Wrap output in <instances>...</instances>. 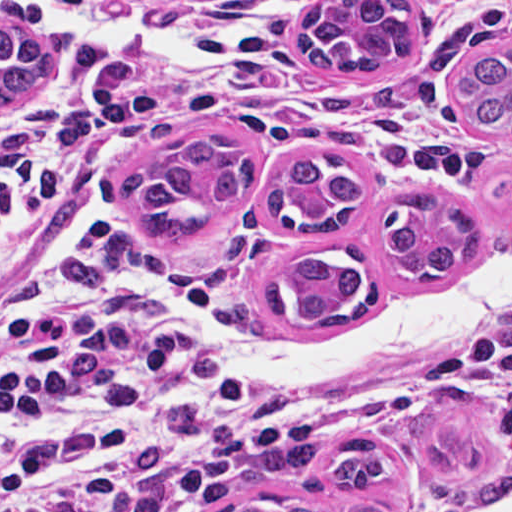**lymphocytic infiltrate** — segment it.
Returning <instances> with one entry per match:
<instances>
[{
    "instance_id": "1",
    "label": "lymphocytic infiltrate",
    "mask_w": 512,
    "mask_h": 512,
    "mask_svg": "<svg viewBox=\"0 0 512 512\" xmlns=\"http://www.w3.org/2000/svg\"><path fill=\"white\" fill-rule=\"evenodd\" d=\"M29 0L0 26L29 29ZM173 261L125 240L32 256L0 281V512H199L345 416L224 373ZM483 321L512 391V289Z\"/></svg>"
}]
</instances>
